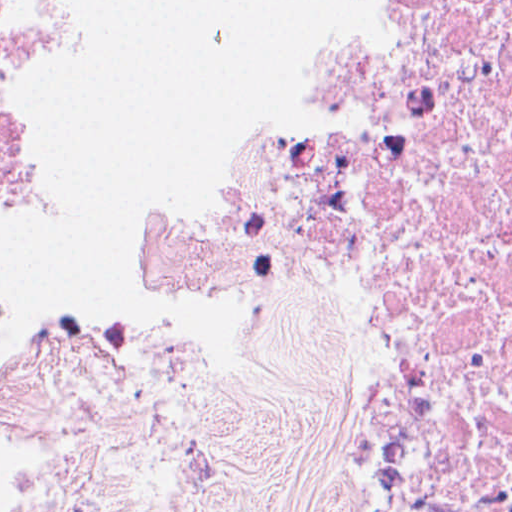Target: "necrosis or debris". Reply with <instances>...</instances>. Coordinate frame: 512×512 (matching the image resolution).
<instances>
[{"instance_id":"necrosis-or-debris-1","label":"necrosis or debris","mask_w":512,"mask_h":512,"mask_svg":"<svg viewBox=\"0 0 512 512\" xmlns=\"http://www.w3.org/2000/svg\"><path fill=\"white\" fill-rule=\"evenodd\" d=\"M156 311L324 363L349 512H512V0H356L238 178L144 242ZM0 512H124L33 478Z\"/></svg>"}]
</instances>
